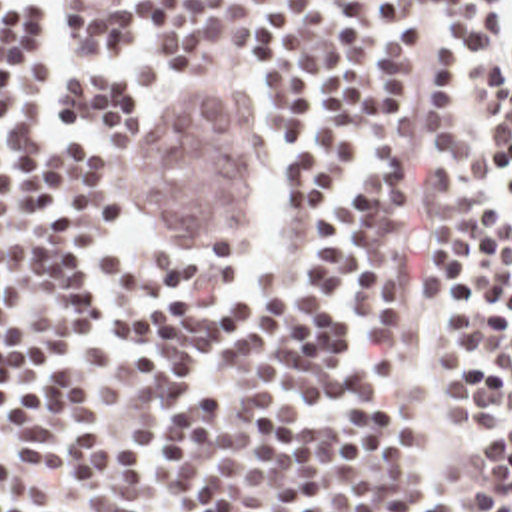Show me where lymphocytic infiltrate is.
<instances>
[{
	"label": "lymphocytic infiltrate",
	"mask_w": 512,
	"mask_h": 512,
	"mask_svg": "<svg viewBox=\"0 0 512 512\" xmlns=\"http://www.w3.org/2000/svg\"><path fill=\"white\" fill-rule=\"evenodd\" d=\"M0 0V512H512V0ZM244 244L138 166L234 86Z\"/></svg>",
	"instance_id": "lymphocytic-infiltrate-1"
}]
</instances>
